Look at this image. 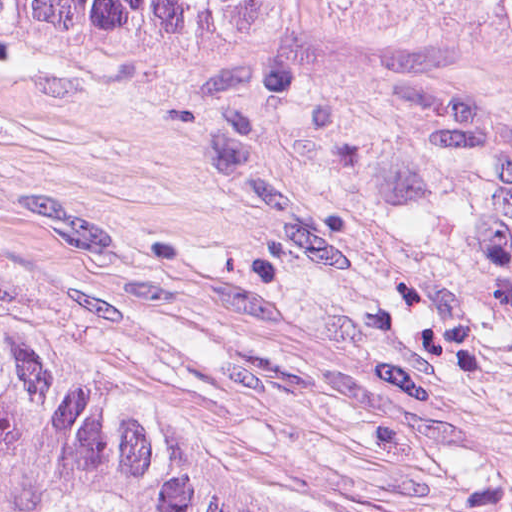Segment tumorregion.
Masks as SVG:
<instances>
[{"label": "tumor region", "mask_w": 512, "mask_h": 512, "mask_svg": "<svg viewBox=\"0 0 512 512\" xmlns=\"http://www.w3.org/2000/svg\"><path fill=\"white\" fill-rule=\"evenodd\" d=\"M161 16H398L512 34V0H0L27 42ZM0 512H380L121 332L0 278Z\"/></svg>", "instance_id": "e687c5a6"}]
</instances>
